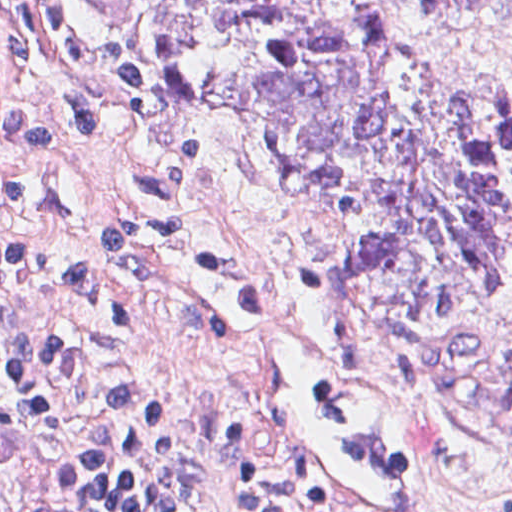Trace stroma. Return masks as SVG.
Here are the masks:
<instances>
[{
    "mask_svg": "<svg viewBox=\"0 0 512 512\" xmlns=\"http://www.w3.org/2000/svg\"><path fill=\"white\" fill-rule=\"evenodd\" d=\"M85 41L141 69L146 102L117 106L73 74L28 0H0V166L5 116L35 111L47 157L20 166L25 205L0 204V245H41L95 271L137 336L182 379L213 450L209 512H233L215 427L237 431L294 489L280 456L263 363L202 328V269L248 253L292 314L369 368L421 463L405 512H512V292L407 318L360 300L343 272L331 188L255 158L197 69L152 60L146 0H67ZM407 57L512 91V30L412 17L391 0H323ZM79 82H75L74 80ZM246 253H245V252Z\"/></svg>",
    "mask_w": 512,
    "mask_h": 512,
    "instance_id": "obj_1",
    "label": "stroma"
}]
</instances>
